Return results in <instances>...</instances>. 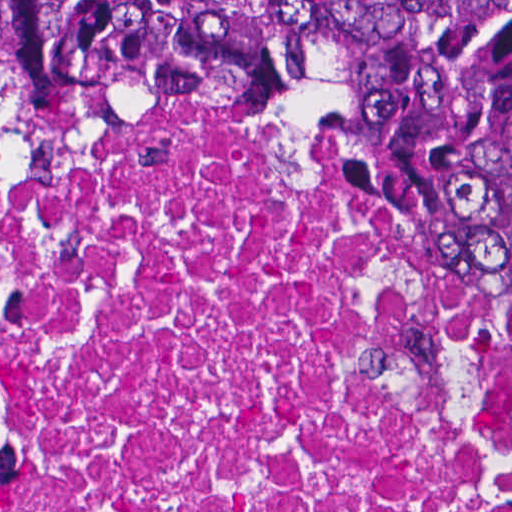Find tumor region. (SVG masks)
<instances>
[{
	"instance_id": "tumor-region-1",
	"label": "tumor region",
	"mask_w": 512,
	"mask_h": 512,
	"mask_svg": "<svg viewBox=\"0 0 512 512\" xmlns=\"http://www.w3.org/2000/svg\"><path fill=\"white\" fill-rule=\"evenodd\" d=\"M319 78L464 293L512 329V1H0V95L121 116Z\"/></svg>"
}]
</instances>
